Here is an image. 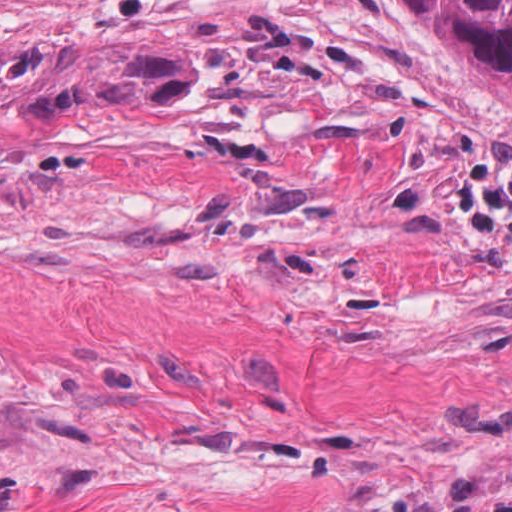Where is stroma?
<instances>
[{"label": "stroma", "instance_id": "stroma-1", "mask_svg": "<svg viewBox=\"0 0 512 512\" xmlns=\"http://www.w3.org/2000/svg\"><path fill=\"white\" fill-rule=\"evenodd\" d=\"M419 512H512V458Z\"/></svg>", "mask_w": 512, "mask_h": 512}]
</instances>
